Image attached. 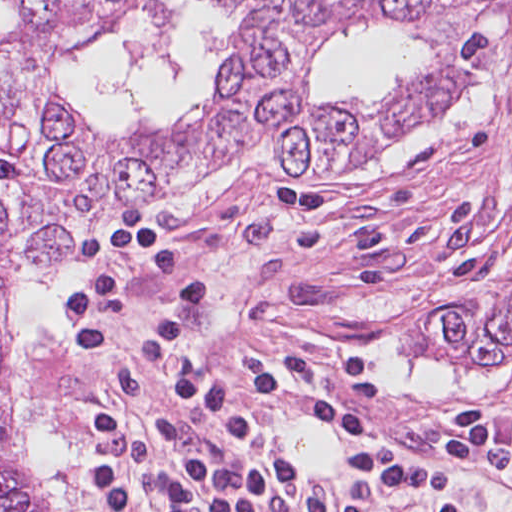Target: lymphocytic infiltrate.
Wrapping results in <instances>:
<instances>
[{
	"label": "lymphocytic infiltrate",
	"mask_w": 512,
	"mask_h": 512,
	"mask_svg": "<svg viewBox=\"0 0 512 512\" xmlns=\"http://www.w3.org/2000/svg\"><path fill=\"white\" fill-rule=\"evenodd\" d=\"M65 285L71 329L50 362L76 512H458L466 463L512 485V429L477 407L445 422L439 460L383 438L309 483L264 416L365 435L390 374L323 342L212 343L209 283L141 204L86 229Z\"/></svg>",
	"instance_id": "f902f5d3"
}]
</instances>
